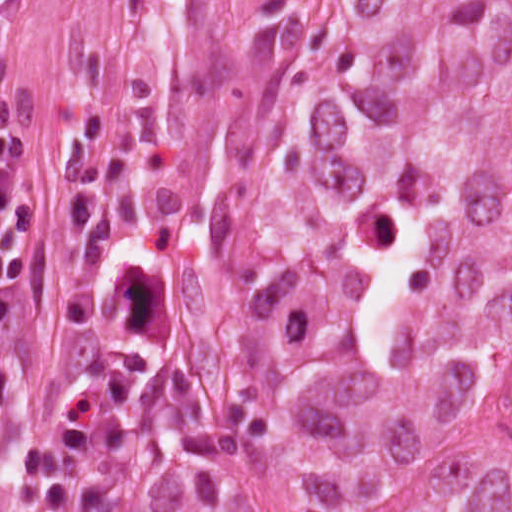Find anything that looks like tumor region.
Wrapping results in <instances>:
<instances>
[{"instance_id": "tumor-region-1", "label": "tumor region", "mask_w": 512, "mask_h": 512, "mask_svg": "<svg viewBox=\"0 0 512 512\" xmlns=\"http://www.w3.org/2000/svg\"><path fill=\"white\" fill-rule=\"evenodd\" d=\"M211 271L284 512H512V1L380 8L222 178ZM71 512H234L170 400L91 417Z\"/></svg>"}]
</instances>
